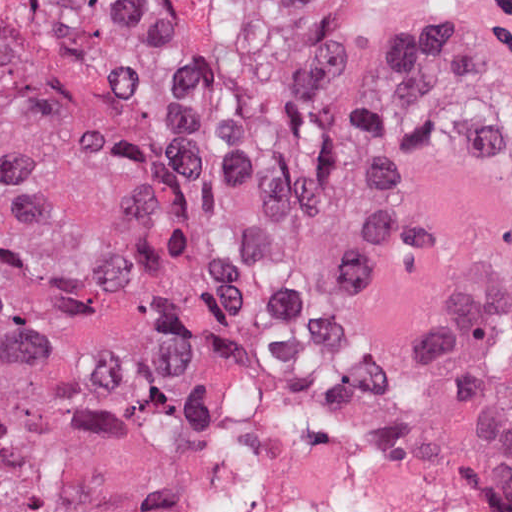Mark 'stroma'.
<instances>
[{"label":"stroma","instance_id":"1","mask_svg":"<svg viewBox=\"0 0 512 512\" xmlns=\"http://www.w3.org/2000/svg\"><path fill=\"white\" fill-rule=\"evenodd\" d=\"M266 24L303 40L356 55L434 70L512 80V47L505 50H397L368 45L291 0H256ZM248 398V464L245 480L228 512H243L257 471L279 435V391L275 356H311L302 347H246L237 350Z\"/></svg>","mask_w":512,"mask_h":512}]
</instances>
